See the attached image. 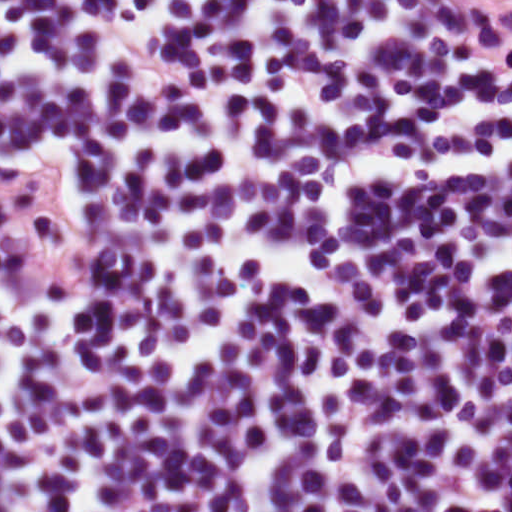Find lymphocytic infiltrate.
Returning <instances> with one entry per match:
<instances>
[{
    "label": "lymphocytic infiltrate",
    "mask_w": 512,
    "mask_h": 512,
    "mask_svg": "<svg viewBox=\"0 0 512 512\" xmlns=\"http://www.w3.org/2000/svg\"><path fill=\"white\" fill-rule=\"evenodd\" d=\"M0 512H456L229 0H0Z\"/></svg>",
    "instance_id": "obj_1"
}]
</instances>
